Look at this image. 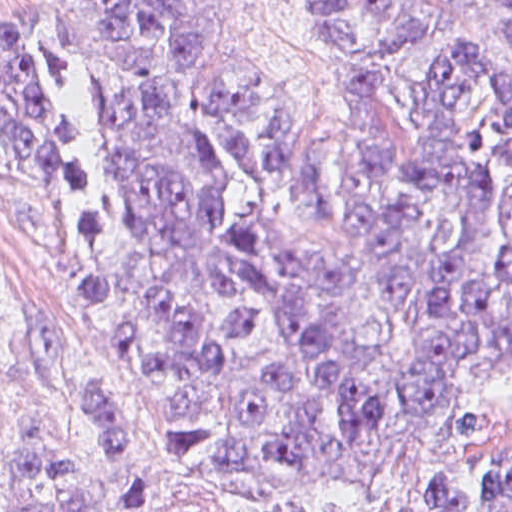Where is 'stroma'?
Here are the masks:
<instances>
[{"instance_id":"1","label":"stroma","mask_w":512,"mask_h":512,"mask_svg":"<svg viewBox=\"0 0 512 512\" xmlns=\"http://www.w3.org/2000/svg\"><path fill=\"white\" fill-rule=\"evenodd\" d=\"M55 0H0V55L38 83L46 131L0 124V512L62 383L125 395L134 442L126 512H299L319 491L384 479L456 445H512V364L336 459L204 473L135 415L84 289L79 217L88 83L54 50ZM237 51L279 113L322 146L339 135V65L302 0H242Z\"/></svg>"}]
</instances>
